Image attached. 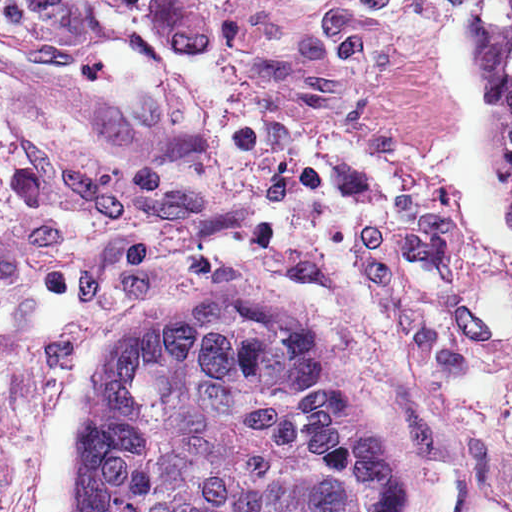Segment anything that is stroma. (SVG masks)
<instances>
[{"label": "stroma", "mask_w": 512, "mask_h": 512, "mask_svg": "<svg viewBox=\"0 0 512 512\" xmlns=\"http://www.w3.org/2000/svg\"><path fill=\"white\" fill-rule=\"evenodd\" d=\"M6 2L121 89L68 103L0 66V512H72L125 325L217 292L86 0Z\"/></svg>", "instance_id": "obj_1"}]
</instances>
